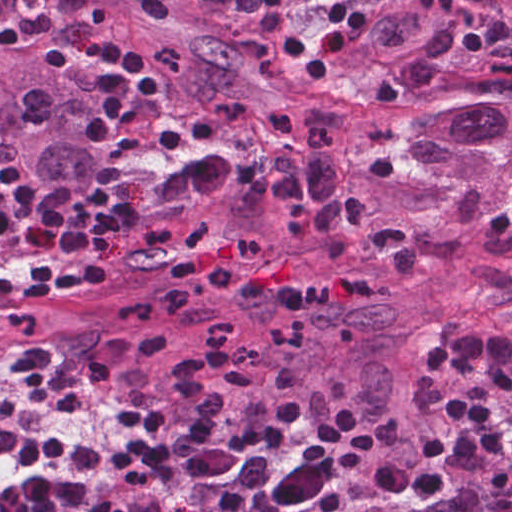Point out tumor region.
Masks as SVG:
<instances>
[{
	"instance_id": "e687c5a6",
	"label": "tumor region",
	"mask_w": 512,
	"mask_h": 512,
	"mask_svg": "<svg viewBox=\"0 0 512 512\" xmlns=\"http://www.w3.org/2000/svg\"><path fill=\"white\" fill-rule=\"evenodd\" d=\"M492 31L481 0H396L364 48L407 97L368 109L333 73H288L258 0H0V166L57 204L127 210L102 286L0 299V369L37 348L49 371H98L154 408ZM107 38L163 79L117 148L84 136ZM88 258L1 239L0 280Z\"/></svg>"
}]
</instances>
